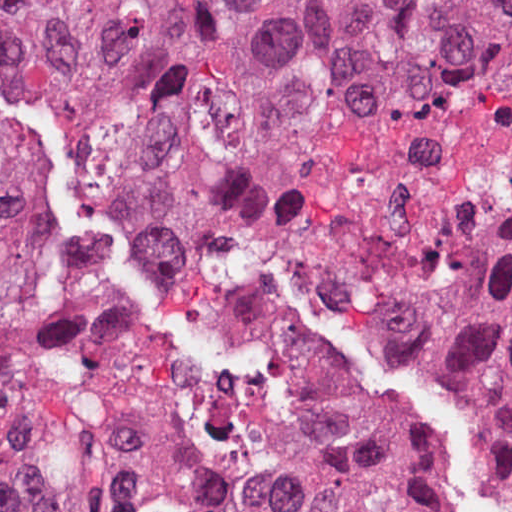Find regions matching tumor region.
I'll use <instances>...</instances> for the list:
<instances>
[{
    "instance_id": "1",
    "label": "tumor region",
    "mask_w": 512,
    "mask_h": 512,
    "mask_svg": "<svg viewBox=\"0 0 512 512\" xmlns=\"http://www.w3.org/2000/svg\"><path fill=\"white\" fill-rule=\"evenodd\" d=\"M512 90V0H0V512L50 480L2 396L21 301L1 128L78 118L119 155L233 173L282 154L393 71ZM340 260L351 344L512 482V234Z\"/></svg>"
}]
</instances>
